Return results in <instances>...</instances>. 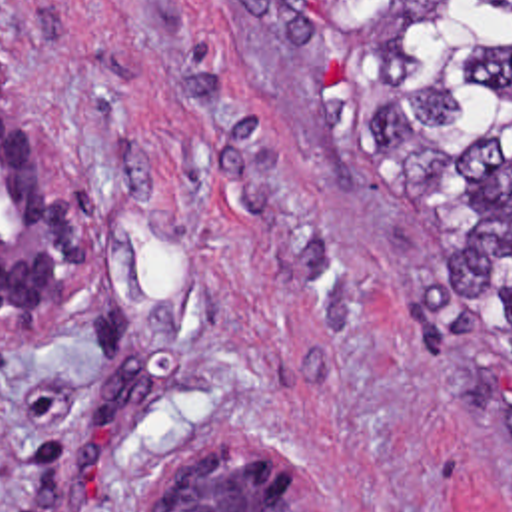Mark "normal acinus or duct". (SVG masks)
<instances>
[{
    "mask_svg": "<svg viewBox=\"0 0 512 512\" xmlns=\"http://www.w3.org/2000/svg\"><path fill=\"white\" fill-rule=\"evenodd\" d=\"M93 270L95 238L17 114L0 54V320L35 316ZM143 512H319V505L295 463L251 443L165 461L143 491Z\"/></svg>",
    "mask_w": 512,
    "mask_h": 512,
    "instance_id": "30e58d81",
    "label": "normal acinus or duct"
}]
</instances>
